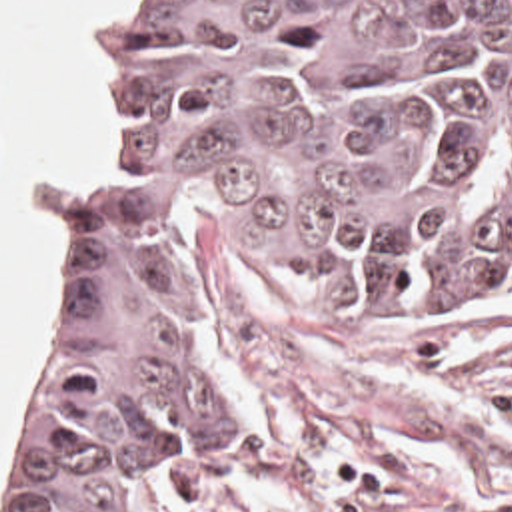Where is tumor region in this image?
Segmentation results:
<instances>
[{
  "label": "tumor region",
  "mask_w": 512,
  "mask_h": 512,
  "mask_svg": "<svg viewBox=\"0 0 512 512\" xmlns=\"http://www.w3.org/2000/svg\"><path fill=\"white\" fill-rule=\"evenodd\" d=\"M0 512H262L186 323L200 201L314 289L512 287V0H120Z\"/></svg>",
  "instance_id": "obj_1"
}]
</instances>
